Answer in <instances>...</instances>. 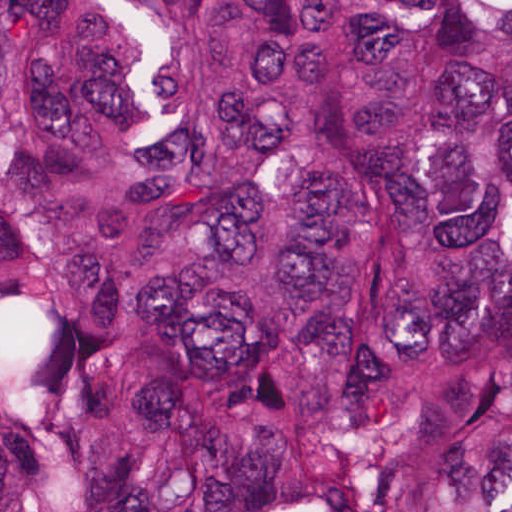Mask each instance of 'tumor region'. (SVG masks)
Masks as SVG:
<instances>
[{
    "instance_id": "tumor-region-1",
    "label": "tumor region",
    "mask_w": 512,
    "mask_h": 512,
    "mask_svg": "<svg viewBox=\"0 0 512 512\" xmlns=\"http://www.w3.org/2000/svg\"><path fill=\"white\" fill-rule=\"evenodd\" d=\"M0 512H512V0H0Z\"/></svg>"
}]
</instances>
